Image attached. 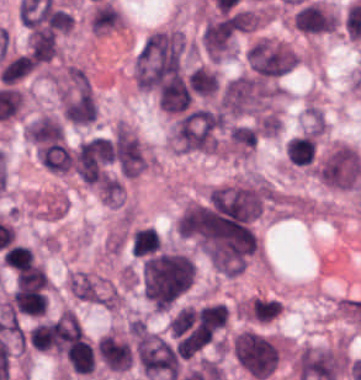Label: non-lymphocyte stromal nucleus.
Returning a JSON list of instances; mask_svg holds the SVG:
<instances>
[{"label": "non-lymphocyte stromal nucleus", "instance_id": "dd21d789", "mask_svg": "<svg viewBox=\"0 0 361 380\" xmlns=\"http://www.w3.org/2000/svg\"><path fill=\"white\" fill-rule=\"evenodd\" d=\"M224 115L212 107H192L182 111L171 125V141L180 152H215Z\"/></svg>", "mask_w": 361, "mask_h": 380}, {"label": "non-lymphocyte stromal nucleus", "instance_id": "a72fc3eb", "mask_svg": "<svg viewBox=\"0 0 361 380\" xmlns=\"http://www.w3.org/2000/svg\"><path fill=\"white\" fill-rule=\"evenodd\" d=\"M244 57L250 75L259 79H272L288 73L297 64L293 51L268 40H255L245 50Z\"/></svg>", "mask_w": 361, "mask_h": 380}, {"label": "non-lymphocyte stromal nucleus", "instance_id": "3746e769", "mask_svg": "<svg viewBox=\"0 0 361 380\" xmlns=\"http://www.w3.org/2000/svg\"><path fill=\"white\" fill-rule=\"evenodd\" d=\"M134 354L142 374L162 380H175L177 355L174 350L154 333L140 332Z\"/></svg>", "mask_w": 361, "mask_h": 380}, {"label": "non-lymphocyte stromal nucleus", "instance_id": "fc2b8d12", "mask_svg": "<svg viewBox=\"0 0 361 380\" xmlns=\"http://www.w3.org/2000/svg\"><path fill=\"white\" fill-rule=\"evenodd\" d=\"M360 173L361 162L355 150L338 145L319 161L317 178L330 189L347 190L357 181Z\"/></svg>", "mask_w": 361, "mask_h": 380}, {"label": "non-lymphocyte stromal nucleus", "instance_id": "81446118", "mask_svg": "<svg viewBox=\"0 0 361 380\" xmlns=\"http://www.w3.org/2000/svg\"><path fill=\"white\" fill-rule=\"evenodd\" d=\"M239 28L226 14H219L208 20L201 44L209 59L219 60L227 54L235 40Z\"/></svg>", "mask_w": 361, "mask_h": 380}, {"label": "non-lymphocyte stromal nucleus", "instance_id": "7c5642bf", "mask_svg": "<svg viewBox=\"0 0 361 380\" xmlns=\"http://www.w3.org/2000/svg\"><path fill=\"white\" fill-rule=\"evenodd\" d=\"M292 26L307 35L332 31V14L321 4L303 1L292 12Z\"/></svg>", "mask_w": 361, "mask_h": 380}, {"label": "non-lymphocyte stromal nucleus", "instance_id": "9d01c50a", "mask_svg": "<svg viewBox=\"0 0 361 380\" xmlns=\"http://www.w3.org/2000/svg\"><path fill=\"white\" fill-rule=\"evenodd\" d=\"M25 133L30 139L37 142L60 138L63 132L54 120L42 115L27 125Z\"/></svg>", "mask_w": 361, "mask_h": 380}]
</instances>
